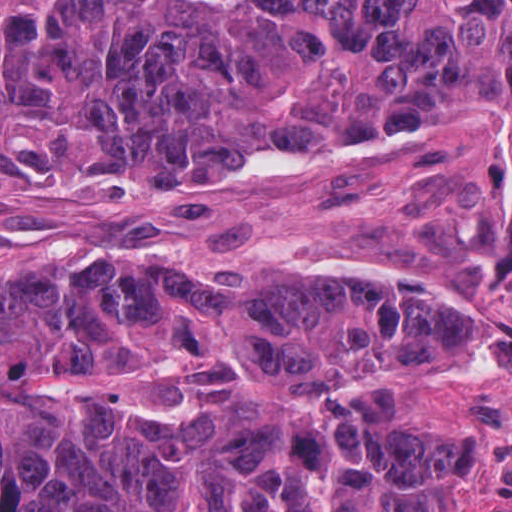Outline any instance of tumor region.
<instances>
[{
    "mask_svg": "<svg viewBox=\"0 0 512 512\" xmlns=\"http://www.w3.org/2000/svg\"><path fill=\"white\" fill-rule=\"evenodd\" d=\"M426 136L512 150V0H0V225L150 236ZM434 279L59 278L0 338L326 385L153 432L0 370V512H446L456 441L390 397L470 351Z\"/></svg>",
    "mask_w": 512,
    "mask_h": 512,
    "instance_id": "obj_1",
    "label": "tumor region"
}]
</instances>
